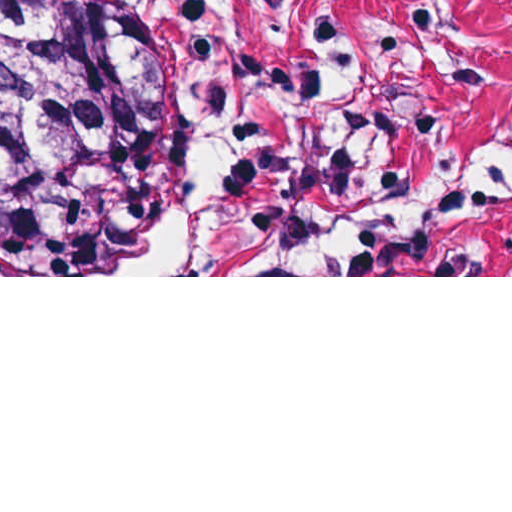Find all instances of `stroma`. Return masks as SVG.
<instances>
[{"label":"stroma","mask_w":512,"mask_h":512,"mask_svg":"<svg viewBox=\"0 0 512 512\" xmlns=\"http://www.w3.org/2000/svg\"><path fill=\"white\" fill-rule=\"evenodd\" d=\"M180 108L179 252L0 277H512V0H105Z\"/></svg>","instance_id":"obj_1"}]
</instances>
